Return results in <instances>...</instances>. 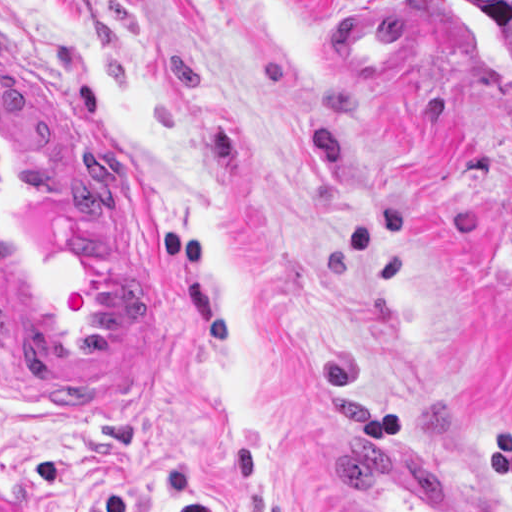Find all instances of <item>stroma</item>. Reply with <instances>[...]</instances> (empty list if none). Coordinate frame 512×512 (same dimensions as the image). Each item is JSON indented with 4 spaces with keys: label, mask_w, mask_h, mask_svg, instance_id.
<instances>
[{
    "label": "stroma",
    "mask_w": 512,
    "mask_h": 512,
    "mask_svg": "<svg viewBox=\"0 0 512 512\" xmlns=\"http://www.w3.org/2000/svg\"><path fill=\"white\" fill-rule=\"evenodd\" d=\"M0 56L137 163L175 349L97 405L0 345V512H339L392 440L512 512V41L458 0H0Z\"/></svg>",
    "instance_id": "1"
}]
</instances>
